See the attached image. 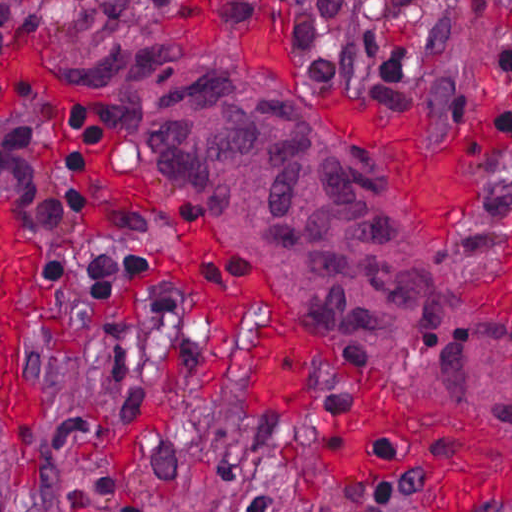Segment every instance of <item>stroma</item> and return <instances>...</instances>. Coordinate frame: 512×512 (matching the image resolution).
Returning <instances> with one entry per match:
<instances>
[{
	"label": "stroma",
	"mask_w": 512,
	"mask_h": 512,
	"mask_svg": "<svg viewBox=\"0 0 512 512\" xmlns=\"http://www.w3.org/2000/svg\"><path fill=\"white\" fill-rule=\"evenodd\" d=\"M14 1L41 10L43 27L19 35L0 60V193L16 200L23 230L39 245L15 302L35 300L44 280L51 301L22 338L23 372L45 389L42 411L15 426L12 450L0 417L7 512H238L256 489V469L247 465L279 479V512H445L414 473L379 475L352 460L346 411L372 390L429 402L505 442L510 499L494 510L512 512V438L500 424L319 349L277 280L193 205L153 186L135 111L84 95L72 75L76 66L131 48L261 74L383 168L438 276L510 322L512 134L388 83L358 46L371 0L346 2L343 69L332 84L309 79L289 27L234 25L201 0H138L110 15L99 0ZM452 2L426 0V22L447 15ZM503 20L506 50L498 20L470 35L466 63L469 81L512 103V6ZM11 91L79 107L103 126L79 253L86 261L150 253L155 272L142 290L109 302L50 278L39 209L4 157ZM343 96L411 106L444 129L476 137V215L462 252L464 232L456 241L439 235L399 159L333 126Z\"/></svg>",
	"instance_id": "obj_1"
}]
</instances>
